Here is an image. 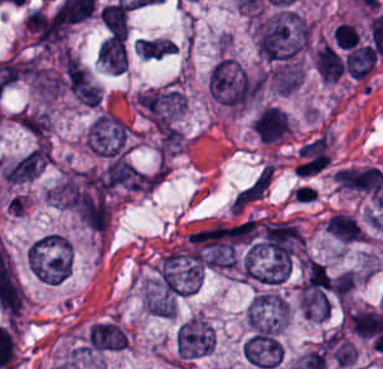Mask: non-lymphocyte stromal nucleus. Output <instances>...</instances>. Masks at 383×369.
<instances>
[{"instance_id": "obj_1", "label": "non-lymphocyte stromal nucleus", "mask_w": 383, "mask_h": 369, "mask_svg": "<svg viewBox=\"0 0 383 369\" xmlns=\"http://www.w3.org/2000/svg\"><path fill=\"white\" fill-rule=\"evenodd\" d=\"M276 170L259 169L248 181H246L233 195L230 200V209L235 212H244L267 195Z\"/></svg>"}]
</instances>
